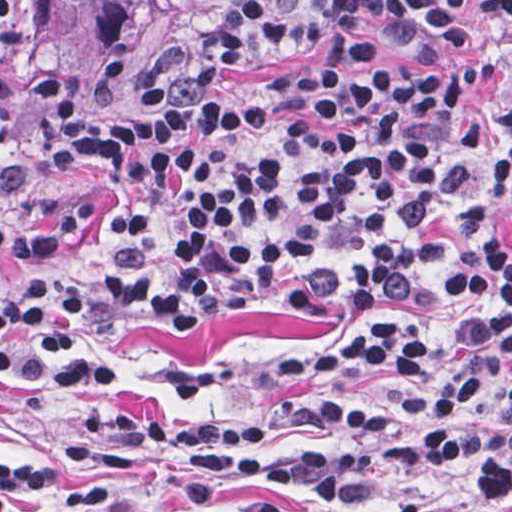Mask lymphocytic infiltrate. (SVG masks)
Wrapping results in <instances>:
<instances>
[{
	"label": "lymphocytic infiltrate",
	"mask_w": 512,
	"mask_h": 512,
	"mask_svg": "<svg viewBox=\"0 0 512 512\" xmlns=\"http://www.w3.org/2000/svg\"><path fill=\"white\" fill-rule=\"evenodd\" d=\"M74 0H0L6 61L24 66L36 145L108 187L44 226L0 227V262L47 267L92 243L101 198L128 197L92 286L121 317H162L266 292L311 296L330 333L278 368L292 419L334 445L282 453L276 424L194 420L106 403L69 431L83 481L33 457L0 460V512H50L163 492L153 512H211L213 489L241 512H285L358 483L382 450L404 463L474 459L477 482L420 512L512 504V395L482 402L512 357V105L488 150L472 93L498 65L468 51L420 67L395 47L458 36L459 0H246L191 23L135 82L122 122L115 87L141 13L170 0H100L84 26L94 70L74 83L37 64L45 9ZM512 10V0H486ZM295 60L254 91L229 66ZM84 283L34 279L0 300V380L46 392L119 383L122 370L78 333Z\"/></svg>",
	"instance_id": "1"
}]
</instances>
